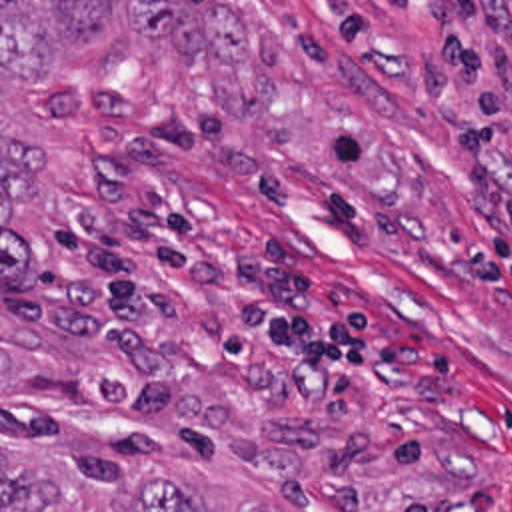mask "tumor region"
Here are the masks:
<instances>
[{"label": "tumor region", "instance_id": "1", "mask_svg": "<svg viewBox=\"0 0 512 512\" xmlns=\"http://www.w3.org/2000/svg\"><path fill=\"white\" fill-rule=\"evenodd\" d=\"M116 16L140 34L162 38L172 54L214 70L238 66L250 50L248 24L218 2H0V76L18 82L58 80ZM52 166L44 144L0 132V285L14 289L28 270V240L12 208L32 204L36 180ZM10 355L0 331V383ZM0 512H200L184 485L164 473L72 453L28 467L0 441ZM238 512H286L270 499H248Z\"/></svg>", "mask_w": 512, "mask_h": 512}]
</instances>
